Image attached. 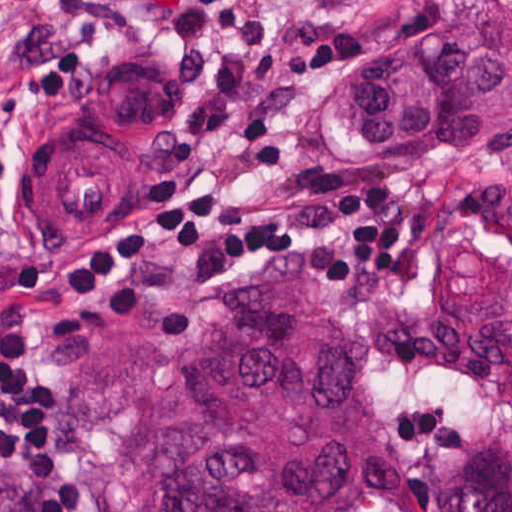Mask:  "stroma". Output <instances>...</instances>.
<instances>
[{"mask_svg":"<svg viewBox=\"0 0 512 512\" xmlns=\"http://www.w3.org/2000/svg\"><path fill=\"white\" fill-rule=\"evenodd\" d=\"M60 1L0 0V52ZM161 1L89 0L96 49L83 84L43 109L28 85L0 121V313L22 320L32 363L55 386V363L88 330L137 328L189 341L255 284L289 277L318 316L354 337L358 386L375 430V489L363 512H433L444 455L462 439L512 423V248L505 245L512 154H357L336 130L350 78L380 47L422 30L433 0H312L294 33L349 27L358 47L305 90L294 179L282 185H252L228 147L192 151L179 142L173 120L188 91L163 81ZM317 170L353 184H389L396 212L427 213V247L410 256L411 275L334 295L303 251L247 264L218 251H157L150 301L134 323L55 304L49 279L57 267L99 236L126 229L129 207L145 211L133 181L179 178L199 193L314 215L326 208L299 197L298 185ZM52 431L56 459L78 474L76 487L95 512H150L138 493L112 495L88 482L59 440L55 412ZM0 483L36 503L19 474L0 468Z\"/></svg>","mask_w":512,"mask_h":512,"instance_id":"1","label":"stroma"}]
</instances>
